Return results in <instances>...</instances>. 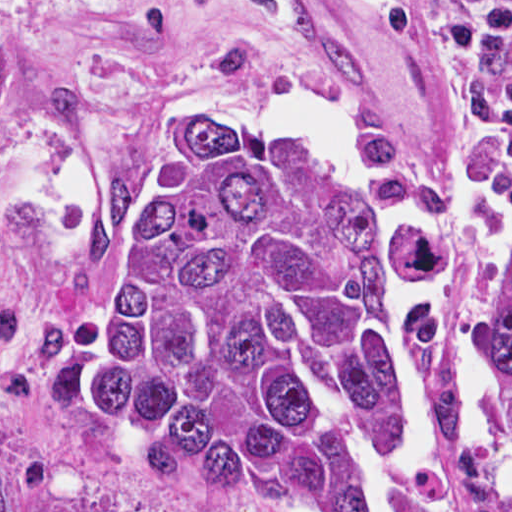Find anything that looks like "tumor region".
Wrapping results in <instances>:
<instances>
[{"label":"tumor region","mask_w":512,"mask_h":512,"mask_svg":"<svg viewBox=\"0 0 512 512\" xmlns=\"http://www.w3.org/2000/svg\"><path fill=\"white\" fill-rule=\"evenodd\" d=\"M510 171L465 195L404 190L446 258L448 415L477 229ZM68 374L113 449L184 489L290 510L512 512V484L446 497L390 464L380 257L341 193L235 105L132 111L103 144L71 248ZM478 389L512 430V298ZM0 512L40 511L0 473Z\"/></svg>","instance_id":"obj_1"}]
</instances>
